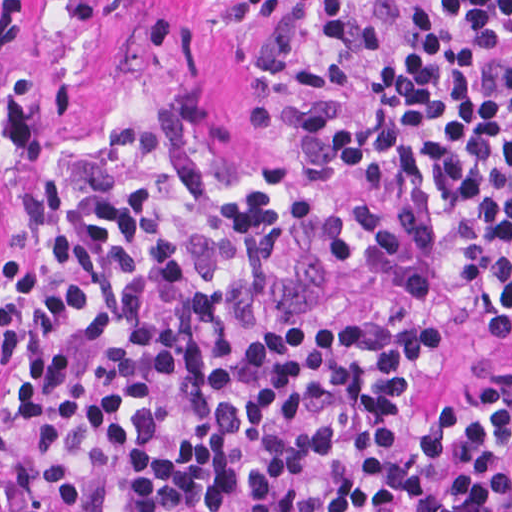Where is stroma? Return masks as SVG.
I'll return each mask as SVG.
<instances>
[{
    "mask_svg": "<svg viewBox=\"0 0 512 512\" xmlns=\"http://www.w3.org/2000/svg\"><path fill=\"white\" fill-rule=\"evenodd\" d=\"M415 1L0 0V292L35 186L91 129L147 100L226 156H287L341 209L358 271L327 310L437 321L444 359L423 377L419 421L512 395V308L458 280L433 187L364 192L306 127L310 112L365 110ZM488 76L512 123V42Z\"/></svg>",
    "mask_w": 512,
    "mask_h": 512,
    "instance_id": "obj_1",
    "label": "stroma"
}]
</instances>
